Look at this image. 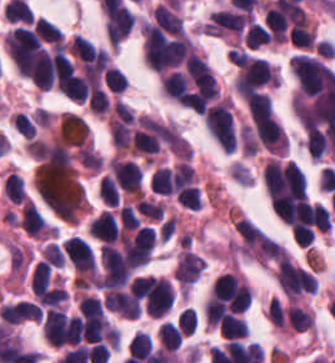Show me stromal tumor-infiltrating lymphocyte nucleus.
I'll return each instance as SVG.
<instances>
[{
    "mask_svg": "<svg viewBox=\"0 0 335 363\" xmlns=\"http://www.w3.org/2000/svg\"><path fill=\"white\" fill-rule=\"evenodd\" d=\"M78 311L81 316H100L104 308L99 297L81 293L78 300Z\"/></svg>",
    "mask_w": 335,
    "mask_h": 363,
    "instance_id": "stromal-tumor-infiltrating-lymphocyte-nucleus-11",
    "label": "stromal tumor-infiltrating lymphocyte nucleus"
},
{
    "mask_svg": "<svg viewBox=\"0 0 335 363\" xmlns=\"http://www.w3.org/2000/svg\"><path fill=\"white\" fill-rule=\"evenodd\" d=\"M150 189L153 193L173 194L172 168L160 166L150 176Z\"/></svg>",
    "mask_w": 335,
    "mask_h": 363,
    "instance_id": "stromal-tumor-infiltrating-lymphocyte-nucleus-4",
    "label": "stromal tumor-infiltrating lymphocyte nucleus"
},
{
    "mask_svg": "<svg viewBox=\"0 0 335 363\" xmlns=\"http://www.w3.org/2000/svg\"><path fill=\"white\" fill-rule=\"evenodd\" d=\"M177 321L185 333L191 334L198 324L196 307L186 306L180 311Z\"/></svg>",
    "mask_w": 335,
    "mask_h": 363,
    "instance_id": "stromal-tumor-infiltrating-lymphocyte-nucleus-16",
    "label": "stromal tumor-infiltrating lymphocyte nucleus"
},
{
    "mask_svg": "<svg viewBox=\"0 0 335 363\" xmlns=\"http://www.w3.org/2000/svg\"><path fill=\"white\" fill-rule=\"evenodd\" d=\"M270 38L271 33L267 28L254 20L245 30L244 42L246 48L256 49L268 43Z\"/></svg>",
    "mask_w": 335,
    "mask_h": 363,
    "instance_id": "stromal-tumor-infiltrating-lymphocyte-nucleus-6",
    "label": "stromal tumor-infiltrating lymphocyte nucleus"
},
{
    "mask_svg": "<svg viewBox=\"0 0 335 363\" xmlns=\"http://www.w3.org/2000/svg\"><path fill=\"white\" fill-rule=\"evenodd\" d=\"M222 336L229 338H242L248 327L243 316L237 313H230L220 322Z\"/></svg>",
    "mask_w": 335,
    "mask_h": 363,
    "instance_id": "stromal-tumor-infiltrating-lymphocyte-nucleus-5",
    "label": "stromal tumor-infiltrating lymphocyte nucleus"
},
{
    "mask_svg": "<svg viewBox=\"0 0 335 363\" xmlns=\"http://www.w3.org/2000/svg\"><path fill=\"white\" fill-rule=\"evenodd\" d=\"M88 225L91 233L103 243H114L119 235L116 218L104 209Z\"/></svg>",
    "mask_w": 335,
    "mask_h": 363,
    "instance_id": "stromal-tumor-infiltrating-lymphocyte-nucleus-2",
    "label": "stromal tumor-infiltrating lymphocyte nucleus"
},
{
    "mask_svg": "<svg viewBox=\"0 0 335 363\" xmlns=\"http://www.w3.org/2000/svg\"><path fill=\"white\" fill-rule=\"evenodd\" d=\"M99 196L108 204L117 206L119 203V190L116 182L109 176L102 175L97 182Z\"/></svg>",
    "mask_w": 335,
    "mask_h": 363,
    "instance_id": "stromal-tumor-infiltrating-lymphocyte-nucleus-10",
    "label": "stromal tumor-infiltrating lymphocyte nucleus"
},
{
    "mask_svg": "<svg viewBox=\"0 0 335 363\" xmlns=\"http://www.w3.org/2000/svg\"><path fill=\"white\" fill-rule=\"evenodd\" d=\"M152 349V338L143 331H136L127 347L128 354L146 359L149 357Z\"/></svg>",
    "mask_w": 335,
    "mask_h": 363,
    "instance_id": "stromal-tumor-infiltrating-lymphocyte-nucleus-9",
    "label": "stromal tumor-infiltrating lymphocyte nucleus"
},
{
    "mask_svg": "<svg viewBox=\"0 0 335 363\" xmlns=\"http://www.w3.org/2000/svg\"><path fill=\"white\" fill-rule=\"evenodd\" d=\"M42 258L50 262L54 267H63L64 255L58 245L48 243L42 251Z\"/></svg>",
    "mask_w": 335,
    "mask_h": 363,
    "instance_id": "stromal-tumor-infiltrating-lymphocyte-nucleus-18",
    "label": "stromal tumor-infiltrating lymphocyte nucleus"
},
{
    "mask_svg": "<svg viewBox=\"0 0 335 363\" xmlns=\"http://www.w3.org/2000/svg\"><path fill=\"white\" fill-rule=\"evenodd\" d=\"M158 340L160 346L168 351H176L180 342V334L178 327L172 321H165L162 323L158 330Z\"/></svg>",
    "mask_w": 335,
    "mask_h": 363,
    "instance_id": "stromal-tumor-infiltrating-lymphocyte-nucleus-7",
    "label": "stromal tumor-infiltrating lymphocyte nucleus"
},
{
    "mask_svg": "<svg viewBox=\"0 0 335 363\" xmlns=\"http://www.w3.org/2000/svg\"><path fill=\"white\" fill-rule=\"evenodd\" d=\"M103 79L107 89L112 93H122L128 84L124 75L113 65L105 71Z\"/></svg>",
    "mask_w": 335,
    "mask_h": 363,
    "instance_id": "stromal-tumor-infiltrating-lymphocyte-nucleus-13",
    "label": "stromal tumor-infiltrating lymphocyte nucleus"
},
{
    "mask_svg": "<svg viewBox=\"0 0 335 363\" xmlns=\"http://www.w3.org/2000/svg\"><path fill=\"white\" fill-rule=\"evenodd\" d=\"M312 224L321 232H329L332 227L331 213L321 203H314L311 208Z\"/></svg>",
    "mask_w": 335,
    "mask_h": 363,
    "instance_id": "stromal-tumor-infiltrating-lymphocyte-nucleus-12",
    "label": "stromal tumor-infiltrating lymphocyte nucleus"
},
{
    "mask_svg": "<svg viewBox=\"0 0 335 363\" xmlns=\"http://www.w3.org/2000/svg\"><path fill=\"white\" fill-rule=\"evenodd\" d=\"M102 304L122 317H138L142 309L139 299L129 288H106Z\"/></svg>",
    "mask_w": 335,
    "mask_h": 363,
    "instance_id": "stromal-tumor-infiltrating-lymphocyte-nucleus-1",
    "label": "stromal tumor-infiltrating lymphocyte nucleus"
},
{
    "mask_svg": "<svg viewBox=\"0 0 335 363\" xmlns=\"http://www.w3.org/2000/svg\"><path fill=\"white\" fill-rule=\"evenodd\" d=\"M52 269L43 258L36 262L31 275V289L49 284Z\"/></svg>",
    "mask_w": 335,
    "mask_h": 363,
    "instance_id": "stromal-tumor-infiltrating-lymphocyte-nucleus-15",
    "label": "stromal tumor-infiltrating lymphocyte nucleus"
},
{
    "mask_svg": "<svg viewBox=\"0 0 335 363\" xmlns=\"http://www.w3.org/2000/svg\"><path fill=\"white\" fill-rule=\"evenodd\" d=\"M33 29L39 40L54 44L63 41V33L61 30L47 18L39 17L34 22Z\"/></svg>",
    "mask_w": 335,
    "mask_h": 363,
    "instance_id": "stromal-tumor-infiltrating-lymphocyte-nucleus-8",
    "label": "stromal tumor-infiltrating lymphocyte nucleus"
},
{
    "mask_svg": "<svg viewBox=\"0 0 335 363\" xmlns=\"http://www.w3.org/2000/svg\"><path fill=\"white\" fill-rule=\"evenodd\" d=\"M122 228L134 229L141 225L139 218L131 204H123L118 211Z\"/></svg>",
    "mask_w": 335,
    "mask_h": 363,
    "instance_id": "stromal-tumor-infiltrating-lymphocyte-nucleus-17",
    "label": "stromal tumor-infiltrating lymphocyte nucleus"
},
{
    "mask_svg": "<svg viewBox=\"0 0 335 363\" xmlns=\"http://www.w3.org/2000/svg\"><path fill=\"white\" fill-rule=\"evenodd\" d=\"M176 196L181 207L197 210L201 208L199 189L196 183L183 188L176 193Z\"/></svg>",
    "mask_w": 335,
    "mask_h": 363,
    "instance_id": "stromal-tumor-infiltrating-lymphocyte-nucleus-14",
    "label": "stromal tumor-infiltrating lymphocyte nucleus"
},
{
    "mask_svg": "<svg viewBox=\"0 0 335 363\" xmlns=\"http://www.w3.org/2000/svg\"><path fill=\"white\" fill-rule=\"evenodd\" d=\"M2 191L13 204H20L27 197L22 177L13 171L3 181Z\"/></svg>",
    "mask_w": 335,
    "mask_h": 363,
    "instance_id": "stromal-tumor-infiltrating-lymphocyte-nucleus-3",
    "label": "stromal tumor-infiltrating lymphocyte nucleus"
}]
</instances>
